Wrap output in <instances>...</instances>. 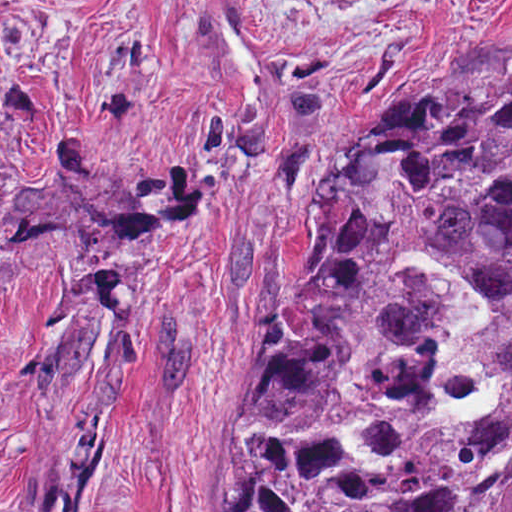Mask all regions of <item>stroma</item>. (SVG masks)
<instances>
[{
	"instance_id": "stroma-1",
	"label": "stroma",
	"mask_w": 512,
	"mask_h": 512,
	"mask_svg": "<svg viewBox=\"0 0 512 512\" xmlns=\"http://www.w3.org/2000/svg\"><path fill=\"white\" fill-rule=\"evenodd\" d=\"M512 79V0H0V512H227L315 165Z\"/></svg>"
}]
</instances>
